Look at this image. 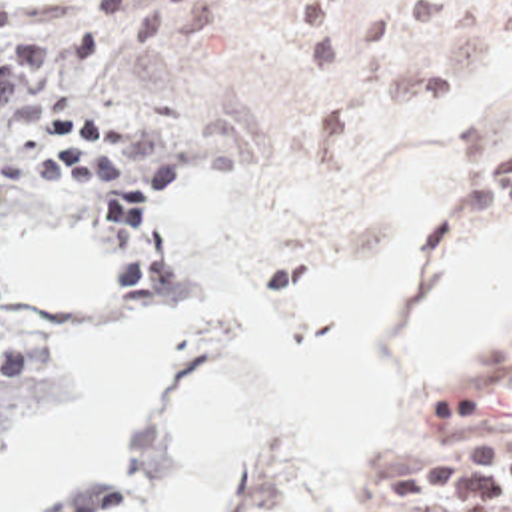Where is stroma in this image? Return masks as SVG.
Listing matches in <instances>:
<instances>
[{
    "label": "stroma",
    "mask_w": 512,
    "mask_h": 512,
    "mask_svg": "<svg viewBox=\"0 0 512 512\" xmlns=\"http://www.w3.org/2000/svg\"><path fill=\"white\" fill-rule=\"evenodd\" d=\"M88 2L0 0L30 18ZM209 10L213 28L187 46L117 48L54 80L74 94L66 110L113 120L123 164L155 168L161 152H175L179 178L145 232L117 236L100 180H42L38 168L54 156L44 122L0 142V216L66 224L111 254L109 316L46 310L16 288L58 364L54 398L74 386L68 348L185 316L213 286L245 288L309 342L319 320L293 302L299 272L385 232L413 184L437 186L451 204L429 262L459 234L512 228V208L461 210L457 200L467 172L512 150V0H219ZM511 366L512 340L457 390L421 394L405 372L401 318L393 428L351 462L363 510L459 512L447 502L385 506L371 492L389 476L443 464L453 450L431 424L443 402ZM221 380L249 392V446L227 468L225 500V512H249L281 410L261 382L213 358L175 370L139 442L46 512H76L125 478ZM303 508L321 512L315 502Z\"/></svg>",
    "instance_id": "obj_1"
}]
</instances>
